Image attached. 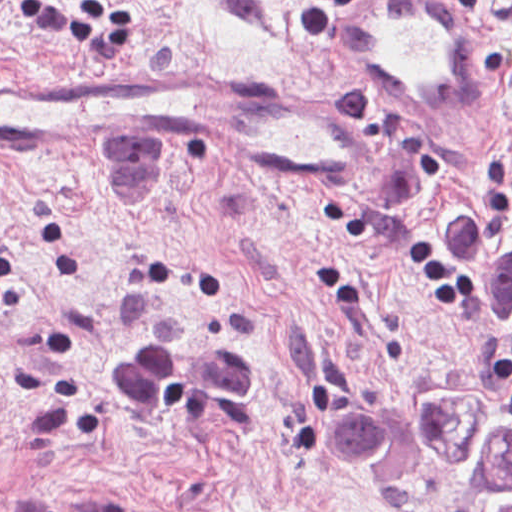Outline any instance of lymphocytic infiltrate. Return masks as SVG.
Here are the masks:
<instances>
[{"mask_svg":"<svg viewBox=\"0 0 512 512\" xmlns=\"http://www.w3.org/2000/svg\"><path fill=\"white\" fill-rule=\"evenodd\" d=\"M354 0H309L308 11L298 26L306 36H324L333 31L340 10ZM459 3H479L482 0H454Z\"/></svg>","mask_w":512,"mask_h":512,"instance_id":"obj_1","label":"lymphocytic infiltrate"}]
</instances>
